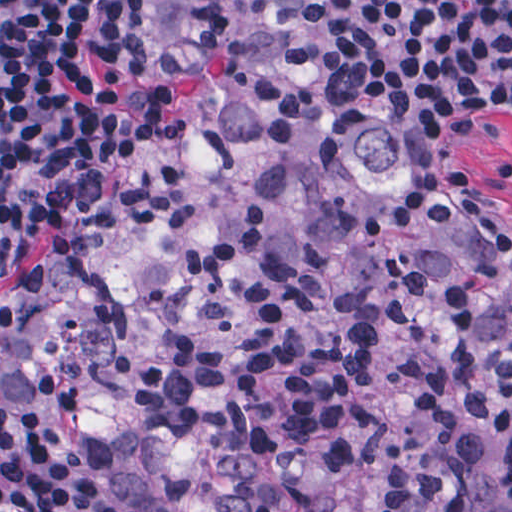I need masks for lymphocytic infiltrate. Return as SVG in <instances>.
<instances>
[{
	"label": "lymphocytic infiltrate",
	"mask_w": 512,
	"mask_h": 512,
	"mask_svg": "<svg viewBox=\"0 0 512 512\" xmlns=\"http://www.w3.org/2000/svg\"><path fill=\"white\" fill-rule=\"evenodd\" d=\"M399 43L458 70L512 66V0H369ZM166 0H0V319L110 191L161 89ZM0 512H136L75 437L0 388Z\"/></svg>",
	"instance_id": "1"
}]
</instances>
